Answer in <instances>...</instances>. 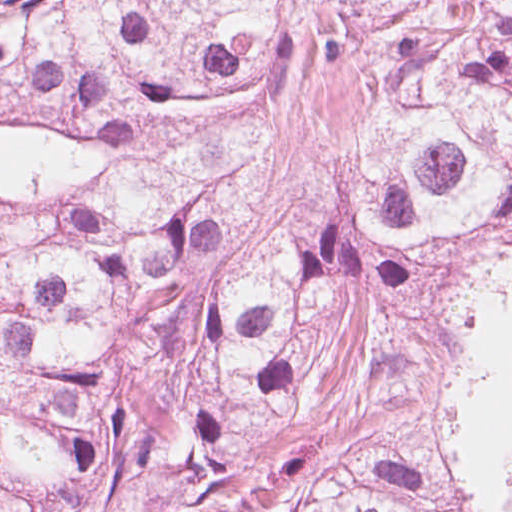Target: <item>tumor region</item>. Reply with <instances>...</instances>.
<instances>
[{
	"mask_svg": "<svg viewBox=\"0 0 512 512\" xmlns=\"http://www.w3.org/2000/svg\"><path fill=\"white\" fill-rule=\"evenodd\" d=\"M363 393L316 484L227 512H482L435 414ZM324 379L0 273V512H220Z\"/></svg>",
	"mask_w": 512,
	"mask_h": 512,
	"instance_id": "e687c5a6",
	"label": "tumor region"
}]
</instances>
